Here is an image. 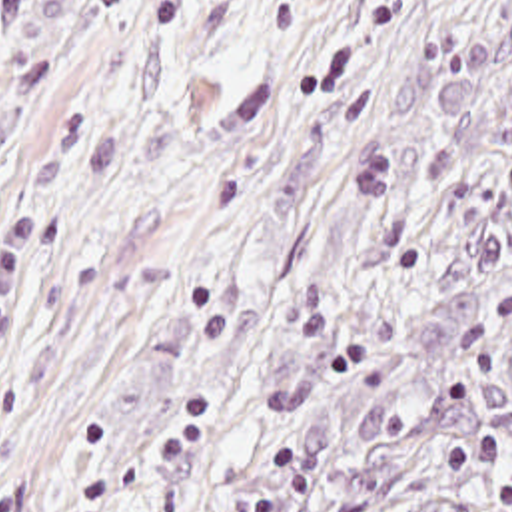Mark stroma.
Listing matches in <instances>:
<instances>
[{
    "label": "stroma",
    "instance_id": "obj_1",
    "mask_svg": "<svg viewBox=\"0 0 512 512\" xmlns=\"http://www.w3.org/2000/svg\"><path fill=\"white\" fill-rule=\"evenodd\" d=\"M510 77L512 0H0V512H153Z\"/></svg>",
    "mask_w": 512,
    "mask_h": 512
}]
</instances>
